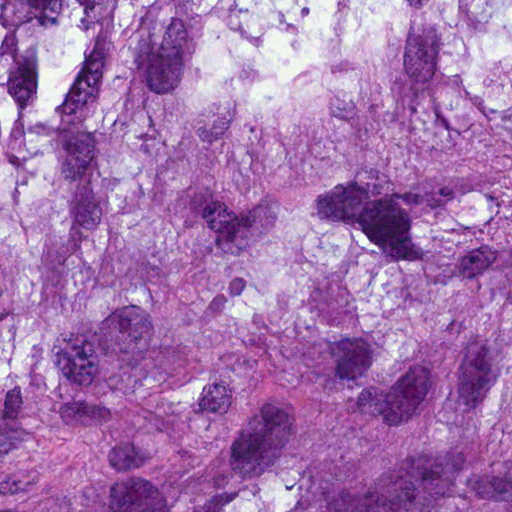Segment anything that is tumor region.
<instances>
[{"instance_id":"tumor-region-1","label":"tumor region","mask_w":512,"mask_h":512,"mask_svg":"<svg viewBox=\"0 0 512 512\" xmlns=\"http://www.w3.org/2000/svg\"><path fill=\"white\" fill-rule=\"evenodd\" d=\"M0 512H512V0H0Z\"/></svg>"}]
</instances>
